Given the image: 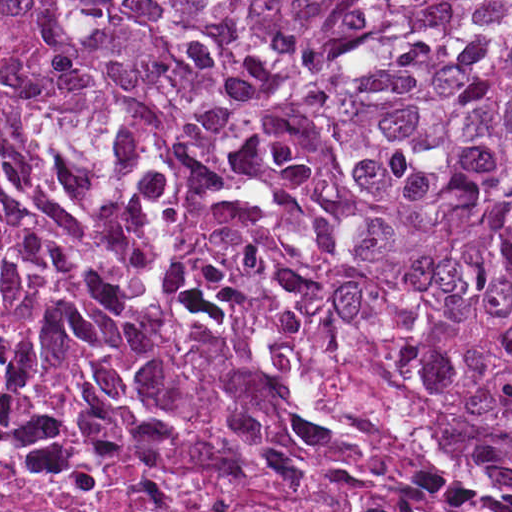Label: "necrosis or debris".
Returning a JSON list of instances; mask_svg holds the SVG:
<instances>
[{"mask_svg": "<svg viewBox=\"0 0 512 512\" xmlns=\"http://www.w3.org/2000/svg\"><path fill=\"white\" fill-rule=\"evenodd\" d=\"M0 512H512V440L202 269L0 38Z\"/></svg>", "mask_w": 512, "mask_h": 512, "instance_id": "1", "label": "necrosis or debris"}]
</instances>
